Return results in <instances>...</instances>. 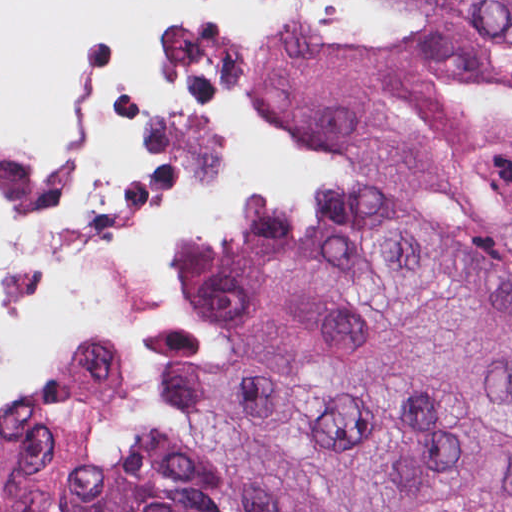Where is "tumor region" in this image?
<instances>
[{
    "label": "tumor region",
    "mask_w": 512,
    "mask_h": 512,
    "mask_svg": "<svg viewBox=\"0 0 512 512\" xmlns=\"http://www.w3.org/2000/svg\"><path fill=\"white\" fill-rule=\"evenodd\" d=\"M411 33L263 69L343 171L334 211L258 196L173 296L214 365L142 331L169 435L118 453L65 359L0 393V512H512V0H390Z\"/></svg>",
    "instance_id": "e687c5a6"
}]
</instances>
